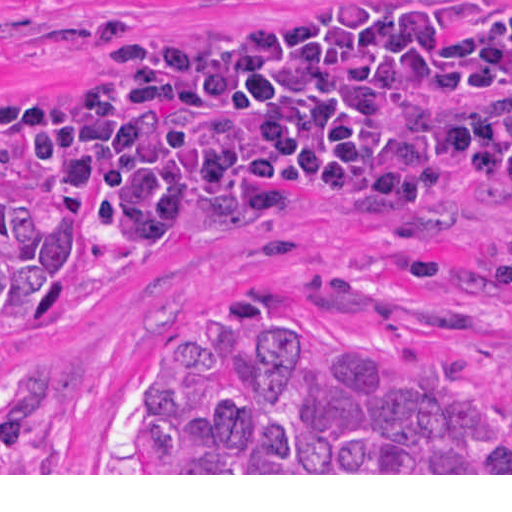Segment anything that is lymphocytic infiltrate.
I'll return each instance as SVG.
<instances>
[{"label":"lymphocytic infiltrate","instance_id":"lymphocytic-infiltrate-1","mask_svg":"<svg viewBox=\"0 0 512 512\" xmlns=\"http://www.w3.org/2000/svg\"><path fill=\"white\" fill-rule=\"evenodd\" d=\"M292 10L281 15L275 22H278V21H281V20H284V19H287L289 18L290 14H291ZM274 22V23H275ZM273 24V23H271ZM269 24V25H271ZM269 25H266L264 27H262L259 31L263 30L264 28L268 27ZM108 26H117L115 23L111 24V25H108ZM99 30V29H98ZM96 30V31H98ZM94 31V33L96 32ZM258 31V32H259ZM257 32V33H258ZM188 39H195V40H200V41H207V40H202V39H197V38H188ZM78 85H75L73 87H70L68 89H64V90H59V91H53V92H46V93H60V92H65V91H70V90H73L74 88H76ZM14 93H38V92H31V91H23V92H14ZM23 169V168H22ZM23 171L26 173V175L33 181L34 184L36 185H40V186H43V187H47V188H51V187H48L46 185H43L41 183H39L37 180H35L33 178V176L31 174H29L28 172H26L24 169ZM480 178H483L485 180H488L498 186H511L512 185V180H509V179H502V178H496V177H480ZM53 189V188H52ZM343 196L347 197L349 200H351L354 204H356L357 206L363 208L364 210L368 211V212H389V211H384V210H379V209H375L371 206H368L366 204H364L363 202H361L359 199H357L355 196H353L352 194H342ZM419 204H424V203H419ZM77 209V208H76ZM403 210H399V211H394V212H401ZM77 212H78V215H79V218L80 220L91 230V231H97L95 227H93V225L88 221V219L77 209ZM185 246L183 247H180V248H184ZM180 248H177V249H180Z\"/></svg>","mask_w":512,"mask_h":512}]
</instances>
